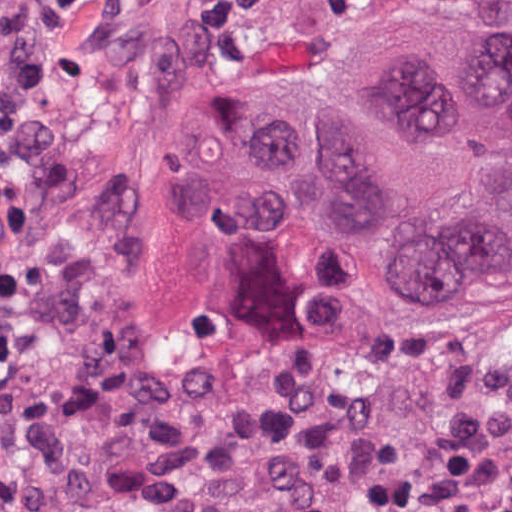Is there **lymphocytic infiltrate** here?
I'll use <instances>...</instances> for the list:
<instances>
[{
	"label": "lymphocytic infiltrate",
	"mask_w": 512,
	"mask_h": 512,
	"mask_svg": "<svg viewBox=\"0 0 512 512\" xmlns=\"http://www.w3.org/2000/svg\"><path fill=\"white\" fill-rule=\"evenodd\" d=\"M23 267L0 283V466L34 358L36 314L18 284ZM366 512H483L453 462L405 469L377 485Z\"/></svg>",
	"instance_id": "f902f5d3"
}]
</instances>
